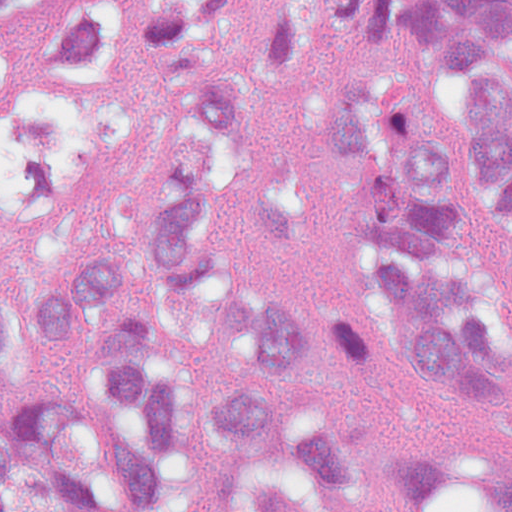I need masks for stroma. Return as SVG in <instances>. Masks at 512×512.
I'll return each instance as SVG.
<instances>
[{"instance_id":"stroma-1","label":"stroma","mask_w":512,"mask_h":512,"mask_svg":"<svg viewBox=\"0 0 512 512\" xmlns=\"http://www.w3.org/2000/svg\"><path fill=\"white\" fill-rule=\"evenodd\" d=\"M291 7L307 24L312 57L258 109V135L267 153L297 175L309 220V242L297 251H273L253 223L237 229L234 264L240 279L313 316L348 314L345 227L351 206L330 176L317 119V100L334 77L388 75L419 89L459 147V185L485 245L494 273V308L512 335V281L504 272V248L512 234V205L488 201L472 159V127L459 69L429 40L419 21L398 14L392 33L373 41L354 38L331 21V0H249L234 25L257 22ZM220 375L265 396L304 406L345 424L360 447L385 444H451L481 447L500 428L472 409H448L432 400L381 347L372 383L321 379L309 391H269L211 362ZM0 437L51 462L71 491L78 512H87L48 455L5 427ZM196 512H394L379 500L335 508L305 488L295 469L261 457H239L217 496Z\"/></svg>"}]
</instances>
